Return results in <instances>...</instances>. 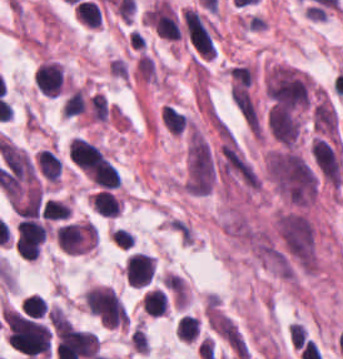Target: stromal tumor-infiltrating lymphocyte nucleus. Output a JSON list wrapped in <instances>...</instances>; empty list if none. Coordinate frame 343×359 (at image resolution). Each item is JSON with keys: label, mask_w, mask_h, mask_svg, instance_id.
Instances as JSON below:
<instances>
[{"label": "stromal tumor-infiltrating lymphocyte nucleus", "mask_w": 343, "mask_h": 359, "mask_svg": "<svg viewBox=\"0 0 343 359\" xmlns=\"http://www.w3.org/2000/svg\"><path fill=\"white\" fill-rule=\"evenodd\" d=\"M144 312L159 316L166 310L165 294L158 288L150 289L143 296Z\"/></svg>", "instance_id": "stromal-tumor-infiltrating-lymphocyte-nucleus-7"}, {"label": "stromal tumor-infiltrating lymphocyte nucleus", "mask_w": 343, "mask_h": 359, "mask_svg": "<svg viewBox=\"0 0 343 359\" xmlns=\"http://www.w3.org/2000/svg\"><path fill=\"white\" fill-rule=\"evenodd\" d=\"M85 98L82 88H75L65 99L61 109L62 116H73L83 113Z\"/></svg>", "instance_id": "stromal-tumor-infiltrating-lymphocyte-nucleus-10"}, {"label": "stromal tumor-infiltrating lymphocyte nucleus", "mask_w": 343, "mask_h": 359, "mask_svg": "<svg viewBox=\"0 0 343 359\" xmlns=\"http://www.w3.org/2000/svg\"><path fill=\"white\" fill-rule=\"evenodd\" d=\"M21 308L26 315L41 317L45 312L46 305L38 294H31L23 299L20 303Z\"/></svg>", "instance_id": "stromal-tumor-infiltrating-lymphocyte-nucleus-12"}, {"label": "stromal tumor-infiltrating lymphocyte nucleus", "mask_w": 343, "mask_h": 359, "mask_svg": "<svg viewBox=\"0 0 343 359\" xmlns=\"http://www.w3.org/2000/svg\"><path fill=\"white\" fill-rule=\"evenodd\" d=\"M100 11L92 1H79L75 4V18L89 27L97 26Z\"/></svg>", "instance_id": "stromal-tumor-infiltrating-lymphocyte-nucleus-8"}, {"label": "stromal tumor-infiltrating lymphocyte nucleus", "mask_w": 343, "mask_h": 359, "mask_svg": "<svg viewBox=\"0 0 343 359\" xmlns=\"http://www.w3.org/2000/svg\"><path fill=\"white\" fill-rule=\"evenodd\" d=\"M55 237L60 250L70 255H78L92 248L93 231L90 222L61 225Z\"/></svg>", "instance_id": "stromal-tumor-infiltrating-lymphocyte-nucleus-2"}, {"label": "stromal tumor-infiltrating lymphocyte nucleus", "mask_w": 343, "mask_h": 359, "mask_svg": "<svg viewBox=\"0 0 343 359\" xmlns=\"http://www.w3.org/2000/svg\"><path fill=\"white\" fill-rule=\"evenodd\" d=\"M199 333V319L195 316H181L176 325V337L192 341Z\"/></svg>", "instance_id": "stromal-tumor-infiltrating-lymphocyte-nucleus-9"}, {"label": "stromal tumor-infiltrating lymphocyte nucleus", "mask_w": 343, "mask_h": 359, "mask_svg": "<svg viewBox=\"0 0 343 359\" xmlns=\"http://www.w3.org/2000/svg\"><path fill=\"white\" fill-rule=\"evenodd\" d=\"M34 83L37 92L50 97L60 93L62 73L55 62H41L34 73Z\"/></svg>", "instance_id": "stromal-tumor-infiltrating-lymphocyte-nucleus-4"}, {"label": "stromal tumor-infiltrating lymphocyte nucleus", "mask_w": 343, "mask_h": 359, "mask_svg": "<svg viewBox=\"0 0 343 359\" xmlns=\"http://www.w3.org/2000/svg\"><path fill=\"white\" fill-rule=\"evenodd\" d=\"M69 214L70 212L67 206H65L63 203L48 198L40 210V217L50 221L63 219Z\"/></svg>", "instance_id": "stromal-tumor-infiltrating-lymphocyte-nucleus-11"}, {"label": "stromal tumor-infiltrating lymphocyte nucleus", "mask_w": 343, "mask_h": 359, "mask_svg": "<svg viewBox=\"0 0 343 359\" xmlns=\"http://www.w3.org/2000/svg\"><path fill=\"white\" fill-rule=\"evenodd\" d=\"M32 166L39 178L46 182H57L62 173L60 156L47 148H40L32 159Z\"/></svg>", "instance_id": "stromal-tumor-infiltrating-lymphocyte-nucleus-5"}, {"label": "stromal tumor-infiltrating lymphocyte nucleus", "mask_w": 343, "mask_h": 359, "mask_svg": "<svg viewBox=\"0 0 343 359\" xmlns=\"http://www.w3.org/2000/svg\"><path fill=\"white\" fill-rule=\"evenodd\" d=\"M155 259L151 255L133 252L125 261V281L134 287H141L154 273Z\"/></svg>", "instance_id": "stromal-tumor-infiltrating-lymphocyte-nucleus-3"}, {"label": "stromal tumor-infiltrating lymphocyte nucleus", "mask_w": 343, "mask_h": 359, "mask_svg": "<svg viewBox=\"0 0 343 359\" xmlns=\"http://www.w3.org/2000/svg\"><path fill=\"white\" fill-rule=\"evenodd\" d=\"M82 301L90 315L101 325H127L124 307L111 287H91L86 290Z\"/></svg>", "instance_id": "stromal-tumor-infiltrating-lymphocyte-nucleus-1"}, {"label": "stromal tumor-infiltrating lymphocyte nucleus", "mask_w": 343, "mask_h": 359, "mask_svg": "<svg viewBox=\"0 0 343 359\" xmlns=\"http://www.w3.org/2000/svg\"><path fill=\"white\" fill-rule=\"evenodd\" d=\"M90 203L97 214L104 216H117L120 205L109 190H101L90 197Z\"/></svg>", "instance_id": "stromal-tumor-infiltrating-lymphocyte-nucleus-6"}]
</instances>
